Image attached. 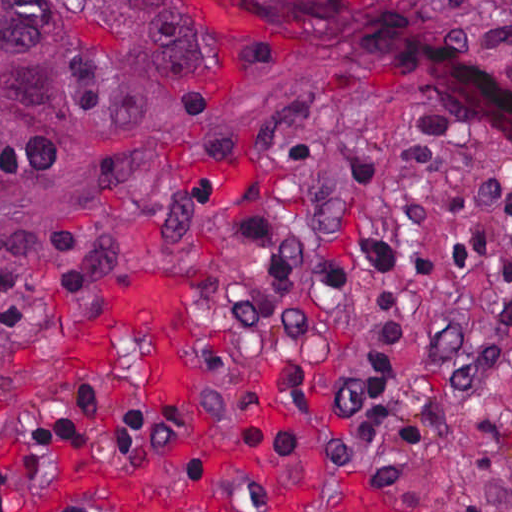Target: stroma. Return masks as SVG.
Listing matches in <instances>:
<instances>
[{
	"mask_svg": "<svg viewBox=\"0 0 512 512\" xmlns=\"http://www.w3.org/2000/svg\"><path fill=\"white\" fill-rule=\"evenodd\" d=\"M378 11L418 22L405 0ZM419 23V22H418ZM429 112L393 75L313 34L232 98L156 113L106 132L62 139L0 193V259L41 251L69 231L93 252V273L68 296L0 328V451L52 428L71 394H117L132 408L182 404L269 420L293 437V459L204 445L223 486L161 459L63 463L27 487L13 512H512V335L501 372L444 403L413 476L329 458L314 424L331 375L365 324L374 282L285 288L238 235L242 206L311 245L379 233L405 245L414 214L401 160ZM512 170L501 151L447 134L437 207L495 185ZM512 263V231L481 265ZM128 270L191 288L200 321L194 393L151 388L158 357L115 332L92 368L68 357L97 289ZM512 300L472 281L432 288L442 316L484 318Z\"/></svg>",
	"mask_w": 512,
	"mask_h": 512,
	"instance_id": "1",
	"label": "stroma"
}]
</instances>
